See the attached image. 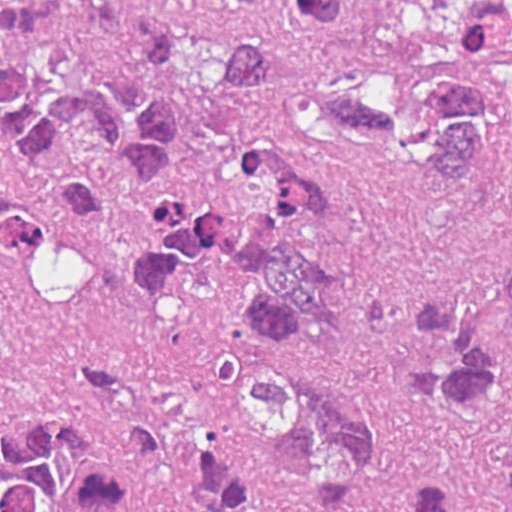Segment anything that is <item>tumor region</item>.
<instances>
[{"label": "tumor region", "instance_id": "tumor-region-1", "mask_svg": "<svg viewBox=\"0 0 512 512\" xmlns=\"http://www.w3.org/2000/svg\"><path fill=\"white\" fill-rule=\"evenodd\" d=\"M296 25L358 47L364 80L301 88L311 128L363 163H404L501 222L490 258L414 307L398 377L446 448L403 512H512V0H482L435 41H387L355 0H285ZM274 49L239 25L149 0H0V143L60 205L98 222L101 149L146 178L152 218L126 295L162 309L235 277L253 313L223 343L187 461L201 512H344L382 476L386 419L345 364L353 189L344 169L262 129ZM54 234L0 152V258ZM74 424L0 444V512H100L119 470Z\"/></svg>", "mask_w": 512, "mask_h": 512}]
</instances>
